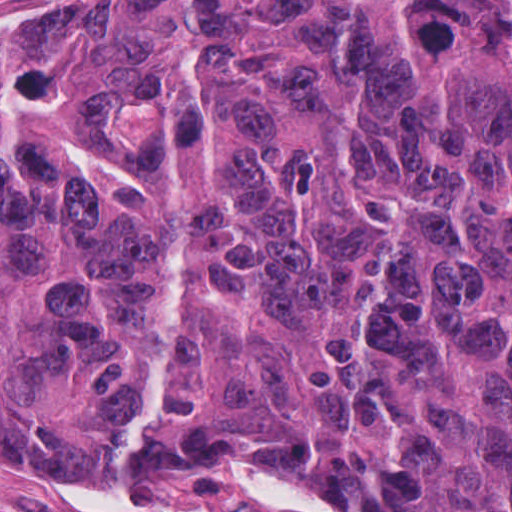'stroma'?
<instances>
[{"mask_svg":"<svg viewBox=\"0 0 512 512\" xmlns=\"http://www.w3.org/2000/svg\"><path fill=\"white\" fill-rule=\"evenodd\" d=\"M122 0H0V65L89 36ZM0 512H363L355 501L269 459L204 451L145 472L51 470L0 460Z\"/></svg>","mask_w":512,"mask_h":512,"instance_id":"stroma-1","label":"stroma"}]
</instances>
